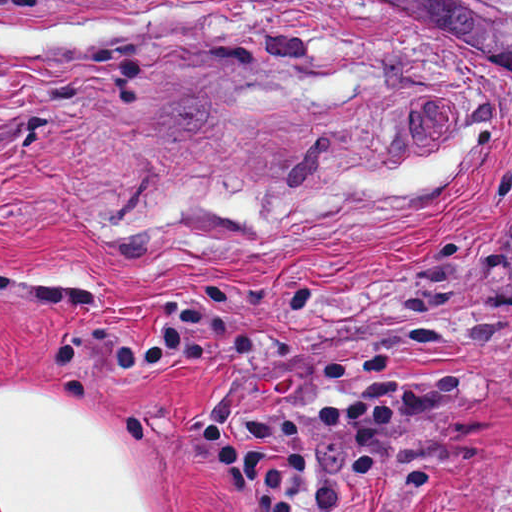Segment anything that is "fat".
Masks as SVG:
<instances>
[{"instance_id":"fat-1","label":"fat","mask_w":512,"mask_h":512,"mask_svg":"<svg viewBox=\"0 0 512 512\" xmlns=\"http://www.w3.org/2000/svg\"><path fill=\"white\" fill-rule=\"evenodd\" d=\"M19 379L0 386V512H169L89 376Z\"/></svg>"}]
</instances>
